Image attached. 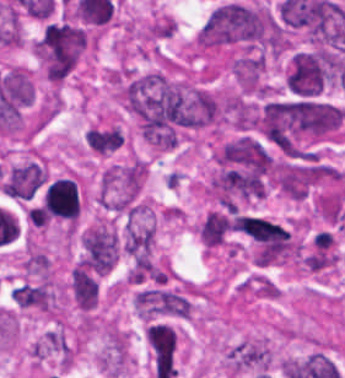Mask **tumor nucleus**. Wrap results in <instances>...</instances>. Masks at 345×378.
Listing matches in <instances>:
<instances>
[{"instance_id":"tumor-nucleus-1","label":"tumor nucleus","mask_w":345,"mask_h":378,"mask_svg":"<svg viewBox=\"0 0 345 378\" xmlns=\"http://www.w3.org/2000/svg\"><path fill=\"white\" fill-rule=\"evenodd\" d=\"M270 158L250 135H237L215 147L206 193L220 202L259 199Z\"/></svg>"},{"instance_id":"tumor-nucleus-2","label":"tumor nucleus","mask_w":345,"mask_h":378,"mask_svg":"<svg viewBox=\"0 0 345 378\" xmlns=\"http://www.w3.org/2000/svg\"><path fill=\"white\" fill-rule=\"evenodd\" d=\"M92 34L81 24L67 19L44 21L35 35L31 54L50 82L62 83L90 47Z\"/></svg>"},{"instance_id":"tumor-nucleus-3","label":"tumor nucleus","mask_w":345,"mask_h":378,"mask_svg":"<svg viewBox=\"0 0 345 378\" xmlns=\"http://www.w3.org/2000/svg\"><path fill=\"white\" fill-rule=\"evenodd\" d=\"M249 45L247 5L230 0L215 7L196 32L194 49L198 51L243 48Z\"/></svg>"},{"instance_id":"tumor-nucleus-4","label":"tumor nucleus","mask_w":345,"mask_h":378,"mask_svg":"<svg viewBox=\"0 0 345 378\" xmlns=\"http://www.w3.org/2000/svg\"><path fill=\"white\" fill-rule=\"evenodd\" d=\"M145 181V166L139 156L109 163L99 173L96 199L106 209L125 212L137 199Z\"/></svg>"},{"instance_id":"tumor-nucleus-5","label":"tumor nucleus","mask_w":345,"mask_h":378,"mask_svg":"<svg viewBox=\"0 0 345 378\" xmlns=\"http://www.w3.org/2000/svg\"><path fill=\"white\" fill-rule=\"evenodd\" d=\"M328 64L329 58L323 49L294 53L285 78L287 88L302 96H315L323 87Z\"/></svg>"},{"instance_id":"tumor-nucleus-6","label":"tumor nucleus","mask_w":345,"mask_h":378,"mask_svg":"<svg viewBox=\"0 0 345 378\" xmlns=\"http://www.w3.org/2000/svg\"><path fill=\"white\" fill-rule=\"evenodd\" d=\"M10 297L17 308L55 313L54 283L48 275L18 282L10 290Z\"/></svg>"},{"instance_id":"tumor-nucleus-7","label":"tumor nucleus","mask_w":345,"mask_h":378,"mask_svg":"<svg viewBox=\"0 0 345 378\" xmlns=\"http://www.w3.org/2000/svg\"><path fill=\"white\" fill-rule=\"evenodd\" d=\"M66 292L76 309L88 312L98 303L99 277L86 263L75 262L70 268Z\"/></svg>"},{"instance_id":"tumor-nucleus-8","label":"tumor nucleus","mask_w":345,"mask_h":378,"mask_svg":"<svg viewBox=\"0 0 345 378\" xmlns=\"http://www.w3.org/2000/svg\"><path fill=\"white\" fill-rule=\"evenodd\" d=\"M43 166L27 161L11 166L0 187L10 196L29 199L47 177Z\"/></svg>"},{"instance_id":"tumor-nucleus-9","label":"tumor nucleus","mask_w":345,"mask_h":378,"mask_svg":"<svg viewBox=\"0 0 345 378\" xmlns=\"http://www.w3.org/2000/svg\"><path fill=\"white\" fill-rule=\"evenodd\" d=\"M87 148L95 154L106 155L118 149L124 142L123 129L113 123H93L85 137Z\"/></svg>"}]
</instances>
